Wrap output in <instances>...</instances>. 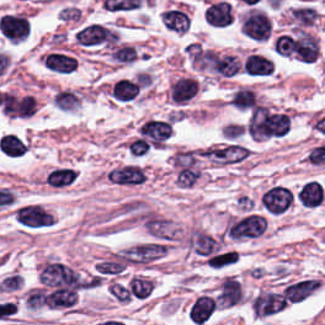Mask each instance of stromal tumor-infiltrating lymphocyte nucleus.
<instances>
[{
    "label": "stromal tumor-infiltrating lymphocyte nucleus",
    "instance_id": "stromal-tumor-infiltrating-lymphocyte-nucleus-1",
    "mask_svg": "<svg viewBox=\"0 0 325 325\" xmlns=\"http://www.w3.org/2000/svg\"><path fill=\"white\" fill-rule=\"evenodd\" d=\"M119 39L117 27L97 20L80 24L73 35V41L87 49H109L118 43Z\"/></svg>",
    "mask_w": 325,
    "mask_h": 325
},
{
    "label": "stromal tumor-infiltrating lymphocyte nucleus",
    "instance_id": "stromal-tumor-infiltrating-lymphocyte-nucleus-2",
    "mask_svg": "<svg viewBox=\"0 0 325 325\" xmlns=\"http://www.w3.org/2000/svg\"><path fill=\"white\" fill-rule=\"evenodd\" d=\"M240 31L256 42H268L274 32L271 12L261 5L246 7L239 18Z\"/></svg>",
    "mask_w": 325,
    "mask_h": 325
},
{
    "label": "stromal tumor-infiltrating lymphocyte nucleus",
    "instance_id": "stromal-tumor-infiltrating-lymphocyte-nucleus-3",
    "mask_svg": "<svg viewBox=\"0 0 325 325\" xmlns=\"http://www.w3.org/2000/svg\"><path fill=\"white\" fill-rule=\"evenodd\" d=\"M13 214L24 229H42L55 223L54 215L40 202H20L14 206Z\"/></svg>",
    "mask_w": 325,
    "mask_h": 325
},
{
    "label": "stromal tumor-infiltrating lymphocyte nucleus",
    "instance_id": "stromal-tumor-infiltrating-lymphocyte-nucleus-4",
    "mask_svg": "<svg viewBox=\"0 0 325 325\" xmlns=\"http://www.w3.org/2000/svg\"><path fill=\"white\" fill-rule=\"evenodd\" d=\"M267 226L263 215L247 214L234 218L229 225V236L233 239H252L262 235Z\"/></svg>",
    "mask_w": 325,
    "mask_h": 325
},
{
    "label": "stromal tumor-infiltrating lymphocyte nucleus",
    "instance_id": "stromal-tumor-infiltrating-lymphocyte-nucleus-5",
    "mask_svg": "<svg viewBox=\"0 0 325 325\" xmlns=\"http://www.w3.org/2000/svg\"><path fill=\"white\" fill-rule=\"evenodd\" d=\"M107 176L108 180L120 186H136L146 182L147 173L140 163L125 162L114 165Z\"/></svg>",
    "mask_w": 325,
    "mask_h": 325
},
{
    "label": "stromal tumor-infiltrating lymphocyte nucleus",
    "instance_id": "stromal-tumor-infiltrating-lymphocyte-nucleus-6",
    "mask_svg": "<svg viewBox=\"0 0 325 325\" xmlns=\"http://www.w3.org/2000/svg\"><path fill=\"white\" fill-rule=\"evenodd\" d=\"M1 32L9 41H23L29 33V19L19 12L1 15Z\"/></svg>",
    "mask_w": 325,
    "mask_h": 325
},
{
    "label": "stromal tumor-infiltrating lymphocyte nucleus",
    "instance_id": "stromal-tumor-infiltrating-lymphocyte-nucleus-7",
    "mask_svg": "<svg viewBox=\"0 0 325 325\" xmlns=\"http://www.w3.org/2000/svg\"><path fill=\"white\" fill-rule=\"evenodd\" d=\"M160 23L168 31L184 33L190 27L189 12L182 6L168 5L161 11Z\"/></svg>",
    "mask_w": 325,
    "mask_h": 325
},
{
    "label": "stromal tumor-infiltrating lymphocyte nucleus",
    "instance_id": "stromal-tumor-infiltrating-lymphocyte-nucleus-8",
    "mask_svg": "<svg viewBox=\"0 0 325 325\" xmlns=\"http://www.w3.org/2000/svg\"><path fill=\"white\" fill-rule=\"evenodd\" d=\"M294 199V195L284 185H275L268 188L262 195L261 201L271 212L287 210Z\"/></svg>",
    "mask_w": 325,
    "mask_h": 325
},
{
    "label": "stromal tumor-infiltrating lymphocyte nucleus",
    "instance_id": "stromal-tumor-infiltrating-lymphocyte-nucleus-9",
    "mask_svg": "<svg viewBox=\"0 0 325 325\" xmlns=\"http://www.w3.org/2000/svg\"><path fill=\"white\" fill-rule=\"evenodd\" d=\"M319 14L317 7L303 3L293 6L288 12L292 27H313Z\"/></svg>",
    "mask_w": 325,
    "mask_h": 325
},
{
    "label": "stromal tumor-infiltrating lymphocyte nucleus",
    "instance_id": "stromal-tumor-infiltrating-lymphocyte-nucleus-10",
    "mask_svg": "<svg viewBox=\"0 0 325 325\" xmlns=\"http://www.w3.org/2000/svg\"><path fill=\"white\" fill-rule=\"evenodd\" d=\"M204 18L214 26H227L232 18L230 3L224 0L212 1L206 9Z\"/></svg>",
    "mask_w": 325,
    "mask_h": 325
},
{
    "label": "stromal tumor-infiltrating lymphocyte nucleus",
    "instance_id": "stromal-tumor-infiltrating-lymphocyte-nucleus-11",
    "mask_svg": "<svg viewBox=\"0 0 325 325\" xmlns=\"http://www.w3.org/2000/svg\"><path fill=\"white\" fill-rule=\"evenodd\" d=\"M141 51L131 43L119 42L108 53L109 60L120 65L136 63Z\"/></svg>",
    "mask_w": 325,
    "mask_h": 325
},
{
    "label": "stromal tumor-infiltrating lymphocyte nucleus",
    "instance_id": "stromal-tumor-infiltrating-lymphocyte-nucleus-12",
    "mask_svg": "<svg viewBox=\"0 0 325 325\" xmlns=\"http://www.w3.org/2000/svg\"><path fill=\"white\" fill-rule=\"evenodd\" d=\"M197 89V82L192 75H178L170 84L171 97L177 101L189 99Z\"/></svg>",
    "mask_w": 325,
    "mask_h": 325
},
{
    "label": "stromal tumor-infiltrating lymphocyte nucleus",
    "instance_id": "stromal-tumor-infiltrating-lymphocyte-nucleus-13",
    "mask_svg": "<svg viewBox=\"0 0 325 325\" xmlns=\"http://www.w3.org/2000/svg\"><path fill=\"white\" fill-rule=\"evenodd\" d=\"M47 69L60 73H69L77 66L76 58L72 54L50 51L46 53L43 60Z\"/></svg>",
    "mask_w": 325,
    "mask_h": 325
},
{
    "label": "stromal tumor-infiltrating lymphocyte nucleus",
    "instance_id": "stromal-tumor-infiltrating-lymphocyte-nucleus-14",
    "mask_svg": "<svg viewBox=\"0 0 325 325\" xmlns=\"http://www.w3.org/2000/svg\"><path fill=\"white\" fill-rule=\"evenodd\" d=\"M244 70L252 75H269L272 73L269 58L256 52L246 56Z\"/></svg>",
    "mask_w": 325,
    "mask_h": 325
},
{
    "label": "stromal tumor-infiltrating lymphocyte nucleus",
    "instance_id": "stromal-tumor-infiltrating-lymphocyte-nucleus-15",
    "mask_svg": "<svg viewBox=\"0 0 325 325\" xmlns=\"http://www.w3.org/2000/svg\"><path fill=\"white\" fill-rule=\"evenodd\" d=\"M139 86L132 80L115 79L112 94L119 99H131L136 95Z\"/></svg>",
    "mask_w": 325,
    "mask_h": 325
}]
</instances>
